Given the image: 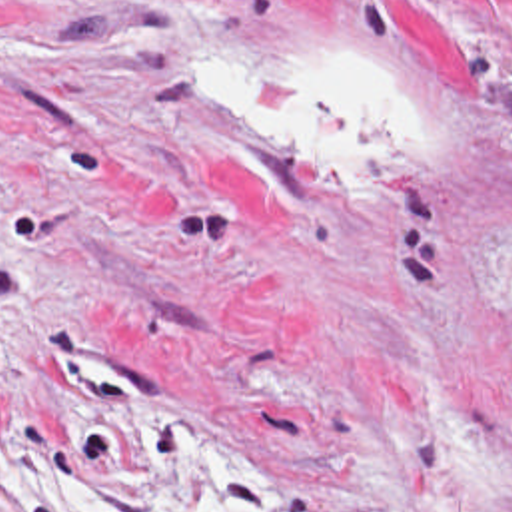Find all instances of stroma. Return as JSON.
I'll return each mask as SVG.
<instances>
[{"instance_id": "obj_1", "label": "stroma", "mask_w": 512, "mask_h": 512, "mask_svg": "<svg viewBox=\"0 0 512 512\" xmlns=\"http://www.w3.org/2000/svg\"><path fill=\"white\" fill-rule=\"evenodd\" d=\"M255 56L377 72L401 175L191 106ZM155 415L251 479L217 512H512V0H0V499Z\"/></svg>"}]
</instances>
